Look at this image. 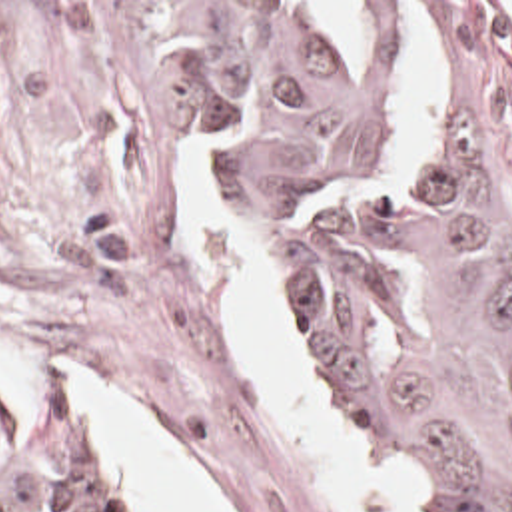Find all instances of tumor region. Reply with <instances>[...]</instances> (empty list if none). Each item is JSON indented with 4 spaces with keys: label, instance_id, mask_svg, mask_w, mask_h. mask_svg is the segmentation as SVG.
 I'll return each mask as SVG.
<instances>
[{
    "label": "tumor region",
    "instance_id": "tumor-region-1",
    "mask_svg": "<svg viewBox=\"0 0 512 512\" xmlns=\"http://www.w3.org/2000/svg\"><path fill=\"white\" fill-rule=\"evenodd\" d=\"M450 98L381 176L385 80L333 66L291 2H163L177 68L291 214L267 240L289 351L424 512H512V184L482 82L450 30ZM395 2H361L387 64ZM0 512H115L93 455L0 381Z\"/></svg>",
    "mask_w": 512,
    "mask_h": 512
}]
</instances>
